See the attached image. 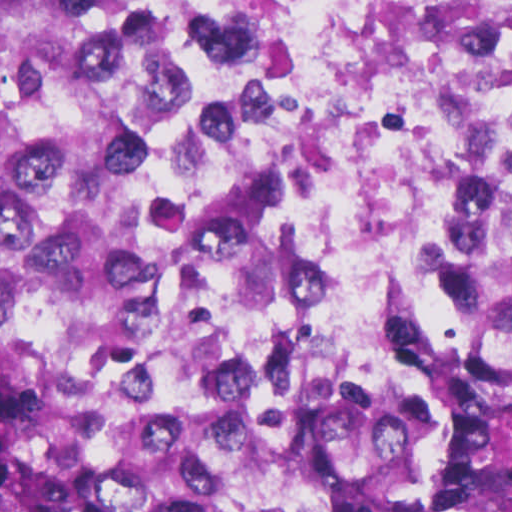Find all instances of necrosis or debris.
<instances>
[{
    "instance_id": "4bbe7bcc",
    "label": "necrosis or debris",
    "mask_w": 512,
    "mask_h": 512,
    "mask_svg": "<svg viewBox=\"0 0 512 512\" xmlns=\"http://www.w3.org/2000/svg\"><path fill=\"white\" fill-rule=\"evenodd\" d=\"M202 261L283 344L400 340L512 178V0H86Z\"/></svg>"
}]
</instances>
